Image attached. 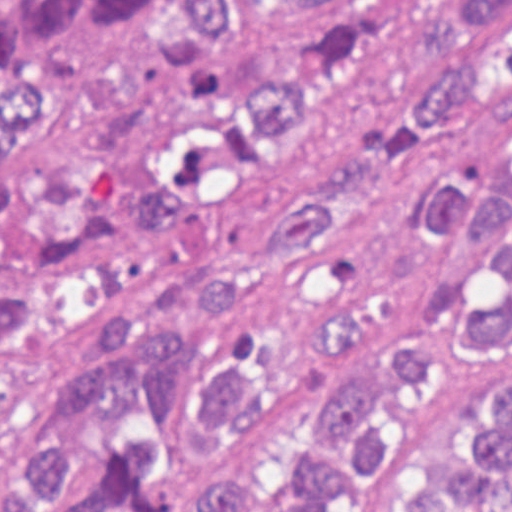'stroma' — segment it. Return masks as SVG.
Instances as JSON below:
<instances>
[{"instance_id": "stroma-1", "label": "stroma", "mask_w": 512, "mask_h": 512, "mask_svg": "<svg viewBox=\"0 0 512 512\" xmlns=\"http://www.w3.org/2000/svg\"><path fill=\"white\" fill-rule=\"evenodd\" d=\"M512 175V95H479L430 147L376 180L327 238L297 255L283 275L217 323L188 362V388L176 429L160 444L125 417H100L86 432L74 492L90 486L113 447L146 438L135 485L160 497L192 494L219 460L223 441L200 422L194 387L203 372L234 367L246 375L258 407L230 427L228 454L256 466L300 467L326 446L324 393L333 378L364 375L395 343L425 324L430 297L462 284L468 314L496 309L509 278L500 244L472 237L471 222L441 243L417 222V205L458 178L480 196ZM512 208V178L493 190ZM512 384V322L507 334L472 340L461 334L431 351L417 376L388 384L378 401L391 432L381 457L353 474L348 490L322 512H355L410 457L435 444L471 391ZM244 481L252 498L272 485L243 470H217ZM212 475V472L210 476ZM206 501V483L176 512ZM59 502V501H58ZM58 502L31 512H51Z\"/></svg>"}]
</instances>
